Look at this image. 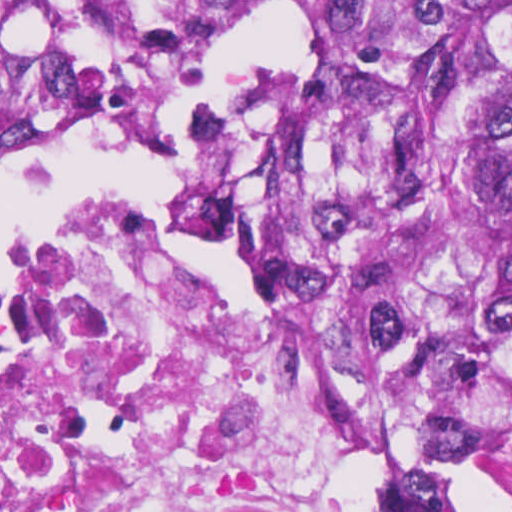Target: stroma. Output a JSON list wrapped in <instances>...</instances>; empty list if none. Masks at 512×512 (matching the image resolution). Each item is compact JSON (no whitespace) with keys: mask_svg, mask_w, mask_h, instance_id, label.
I'll return each mask as SVG.
<instances>
[{"mask_svg":"<svg viewBox=\"0 0 512 512\" xmlns=\"http://www.w3.org/2000/svg\"><path fill=\"white\" fill-rule=\"evenodd\" d=\"M83 1L107 32L99 86L60 140L105 131L155 144L173 103L220 37L253 20H302L313 37L303 62L278 82L237 89L241 166L228 204V263L247 313L292 376L315 425L318 453L338 512H374L406 458L402 431L359 398L323 317L296 270V166L305 128L309 67L330 24L366 1L512 0H0ZM59 140V141H60ZM163 201L107 192L35 234L0 260V280L48 245L118 210ZM466 512H512V416L492 427L460 499Z\"/></svg>","mask_w":512,"mask_h":512,"instance_id":"stroma-1","label":"stroma"}]
</instances>
